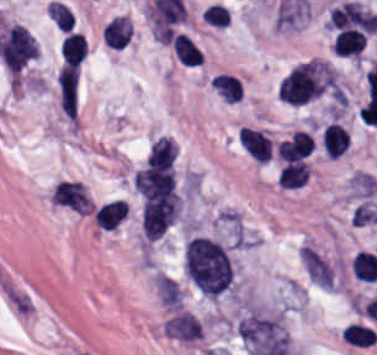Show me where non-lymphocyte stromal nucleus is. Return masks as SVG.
<instances>
[{
	"mask_svg": "<svg viewBox=\"0 0 377 355\" xmlns=\"http://www.w3.org/2000/svg\"><path fill=\"white\" fill-rule=\"evenodd\" d=\"M184 271L208 296L232 290L235 268L230 249L209 234L189 237L184 246Z\"/></svg>",
	"mask_w": 377,
	"mask_h": 355,
	"instance_id": "non-lymphocyte-stromal-nucleus-1",
	"label": "non-lymphocyte stromal nucleus"
},
{
	"mask_svg": "<svg viewBox=\"0 0 377 355\" xmlns=\"http://www.w3.org/2000/svg\"><path fill=\"white\" fill-rule=\"evenodd\" d=\"M49 202L54 207L86 216L95 205L87 185L73 178H60L50 190Z\"/></svg>",
	"mask_w": 377,
	"mask_h": 355,
	"instance_id": "non-lymphocyte-stromal-nucleus-2",
	"label": "non-lymphocyte stromal nucleus"
},
{
	"mask_svg": "<svg viewBox=\"0 0 377 355\" xmlns=\"http://www.w3.org/2000/svg\"><path fill=\"white\" fill-rule=\"evenodd\" d=\"M330 27L373 32L377 13L359 2L347 1L334 6L327 18Z\"/></svg>",
	"mask_w": 377,
	"mask_h": 355,
	"instance_id": "non-lymphocyte-stromal-nucleus-3",
	"label": "non-lymphocyte stromal nucleus"
},
{
	"mask_svg": "<svg viewBox=\"0 0 377 355\" xmlns=\"http://www.w3.org/2000/svg\"><path fill=\"white\" fill-rule=\"evenodd\" d=\"M202 330L199 320L185 310L168 319L165 326L167 337L187 342L199 339Z\"/></svg>",
	"mask_w": 377,
	"mask_h": 355,
	"instance_id": "non-lymphocyte-stromal-nucleus-4",
	"label": "non-lymphocyte stromal nucleus"
},
{
	"mask_svg": "<svg viewBox=\"0 0 377 355\" xmlns=\"http://www.w3.org/2000/svg\"><path fill=\"white\" fill-rule=\"evenodd\" d=\"M302 260L312 280L323 287L333 288L332 270L324 257L306 244L302 250Z\"/></svg>",
	"mask_w": 377,
	"mask_h": 355,
	"instance_id": "non-lymphocyte-stromal-nucleus-5",
	"label": "non-lymphocyte stromal nucleus"
},
{
	"mask_svg": "<svg viewBox=\"0 0 377 355\" xmlns=\"http://www.w3.org/2000/svg\"><path fill=\"white\" fill-rule=\"evenodd\" d=\"M155 286L161 303L168 307H182L183 293L177 280L157 271Z\"/></svg>",
	"mask_w": 377,
	"mask_h": 355,
	"instance_id": "non-lymphocyte-stromal-nucleus-6",
	"label": "non-lymphocyte stromal nucleus"
}]
</instances>
